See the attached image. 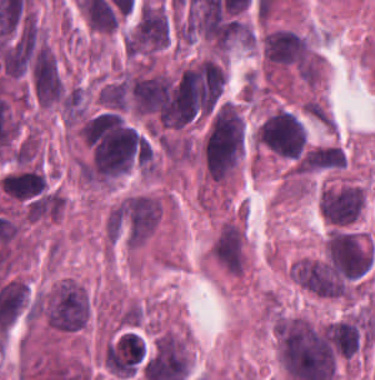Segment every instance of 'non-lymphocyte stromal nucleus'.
Returning a JSON list of instances; mask_svg holds the SVG:
<instances>
[{"mask_svg":"<svg viewBox=\"0 0 375 380\" xmlns=\"http://www.w3.org/2000/svg\"><path fill=\"white\" fill-rule=\"evenodd\" d=\"M302 105L313 119L332 131V117L319 98L310 97Z\"/></svg>","mask_w":375,"mask_h":380,"instance_id":"dd21d789","label":"non-lymphocyte stromal nucleus"}]
</instances>
